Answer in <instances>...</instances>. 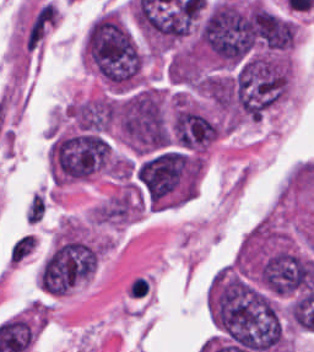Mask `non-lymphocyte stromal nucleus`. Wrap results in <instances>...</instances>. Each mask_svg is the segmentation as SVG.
I'll return each mask as SVG.
<instances>
[{
    "label": "non-lymphocyte stromal nucleus",
    "instance_id": "non-lymphocyte-stromal-nucleus-3",
    "mask_svg": "<svg viewBox=\"0 0 314 352\" xmlns=\"http://www.w3.org/2000/svg\"><path fill=\"white\" fill-rule=\"evenodd\" d=\"M44 213V203L41 195L32 194L24 217L28 222H35L38 218H40Z\"/></svg>",
    "mask_w": 314,
    "mask_h": 352
},
{
    "label": "non-lymphocyte stromal nucleus",
    "instance_id": "non-lymphocyte-stromal-nucleus-1",
    "mask_svg": "<svg viewBox=\"0 0 314 352\" xmlns=\"http://www.w3.org/2000/svg\"><path fill=\"white\" fill-rule=\"evenodd\" d=\"M57 11L54 6L43 2L34 11L22 38L24 46L34 50L54 25Z\"/></svg>",
    "mask_w": 314,
    "mask_h": 352
},
{
    "label": "non-lymphocyte stromal nucleus",
    "instance_id": "non-lymphocyte-stromal-nucleus-2",
    "mask_svg": "<svg viewBox=\"0 0 314 352\" xmlns=\"http://www.w3.org/2000/svg\"><path fill=\"white\" fill-rule=\"evenodd\" d=\"M38 245L35 233L23 232L7 247L6 260L8 265L17 266L33 254Z\"/></svg>",
    "mask_w": 314,
    "mask_h": 352
}]
</instances>
